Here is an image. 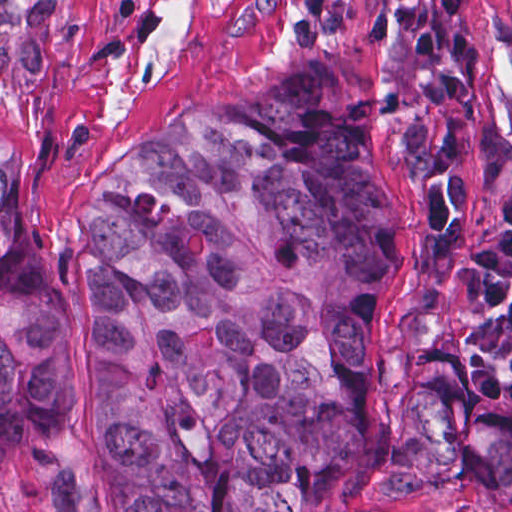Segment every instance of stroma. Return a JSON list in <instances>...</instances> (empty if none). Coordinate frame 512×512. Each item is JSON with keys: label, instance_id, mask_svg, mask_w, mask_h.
Instances as JSON below:
<instances>
[{"label": "stroma", "instance_id": "35a3bbf8", "mask_svg": "<svg viewBox=\"0 0 512 512\" xmlns=\"http://www.w3.org/2000/svg\"><path fill=\"white\" fill-rule=\"evenodd\" d=\"M400 0H0V144L17 162L39 234L47 294L71 316L65 394L46 442L0 467V512H123L96 481L85 426L99 386L94 286L71 250L75 213L99 183H121L159 138L211 102L284 75L341 73L382 115L375 178L396 207L399 269L368 350L388 415L402 408L416 269V175L395 92ZM478 111L512 135V0H476ZM360 512H512L479 474L425 484L367 478Z\"/></svg>", "mask_w": 512, "mask_h": 512}]
</instances>
